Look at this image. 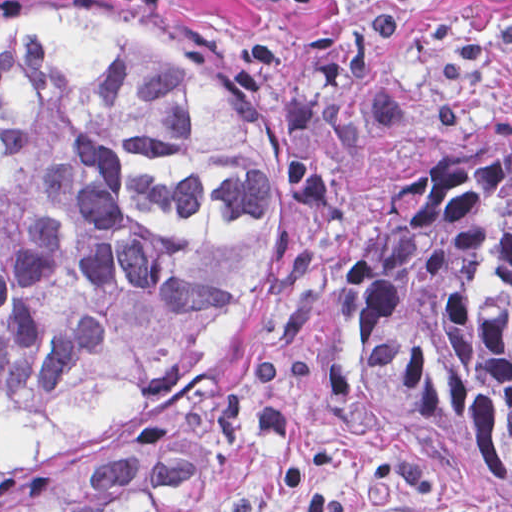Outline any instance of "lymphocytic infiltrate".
<instances>
[{"mask_svg": "<svg viewBox=\"0 0 512 512\" xmlns=\"http://www.w3.org/2000/svg\"><path fill=\"white\" fill-rule=\"evenodd\" d=\"M126 11L147 13L157 7L161 0H112ZM266 4L294 18L308 16L316 0H253ZM470 3H497L502 0H462Z\"/></svg>", "mask_w": 512, "mask_h": 512, "instance_id": "f902f5d3", "label": "lymphocytic infiltrate"}]
</instances>
